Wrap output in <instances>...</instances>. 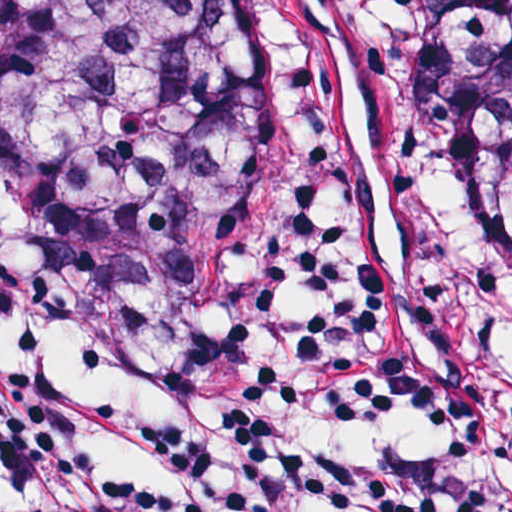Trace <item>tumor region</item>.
Segmentation results:
<instances>
[{
    "mask_svg": "<svg viewBox=\"0 0 512 512\" xmlns=\"http://www.w3.org/2000/svg\"><path fill=\"white\" fill-rule=\"evenodd\" d=\"M408 167L512 308V0L408 7ZM251 0H0V209L155 305L243 292Z\"/></svg>",
    "mask_w": 512,
    "mask_h": 512,
    "instance_id": "tumor-region-1",
    "label": "tumor region"
}]
</instances>
